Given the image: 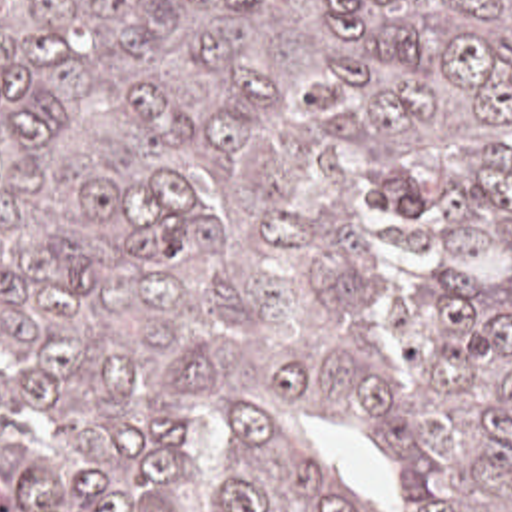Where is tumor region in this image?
<instances>
[{
    "mask_svg": "<svg viewBox=\"0 0 512 512\" xmlns=\"http://www.w3.org/2000/svg\"><path fill=\"white\" fill-rule=\"evenodd\" d=\"M0 512H512V0H0Z\"/></svg>",
    "mask_w": 512,
    "mask_h": 512,
    "instance_id": "obj_1",
    "label": "tumor region"
}]
</instances>
